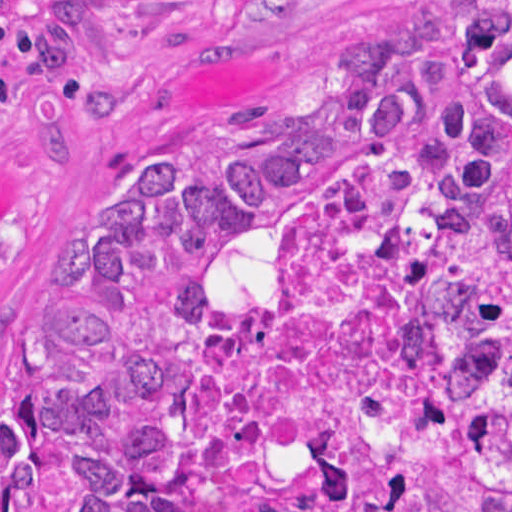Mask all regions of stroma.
<instances>
[{
    "instance_id": "obj_1",
    "label": "stroma",
    "mask_w": 512,
    "mask_h": 512,
    "mask_svg": "<svg viewBox=\"0 0 512 512\" xmlns=\"http://www.w3.org/2000/svg\"><path fill=\"white\" fill-rule=\"evenodd\" d=\"M404 0H0L1 324L45 297L124 149L301 73L355 9Z\"/></svg>"
}]
</instances>
